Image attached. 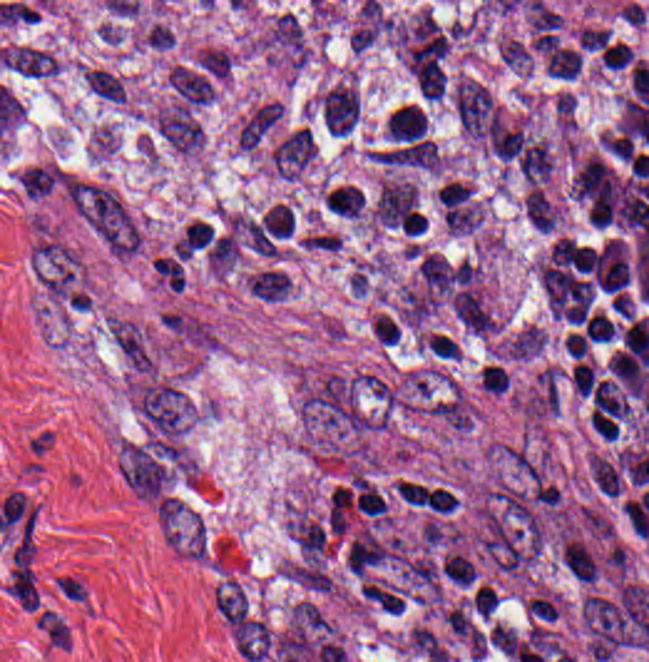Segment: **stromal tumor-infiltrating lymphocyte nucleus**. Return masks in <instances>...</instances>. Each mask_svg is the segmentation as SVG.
I'll list each match as a JSON object with an SVG mask.
<instances>
[{
  "instance_id": "1",
  "label": "stromal tumor-infiltrating lymphocyte nucleus",
  "mask_w": 649,
  "mask_h": 662,
  "mask_svg": "<svg viewBox=\"0 0 649 662\" xmlns=\"http://www.w3.org/2000/svg\"><path fill=\"white\" fill-rule=\"evenodd\" d=\"M452 105L463 131L479 140L490 142L503 125L488 87L475 79L461 80Z\"/></svg>"
}]
</instances>
